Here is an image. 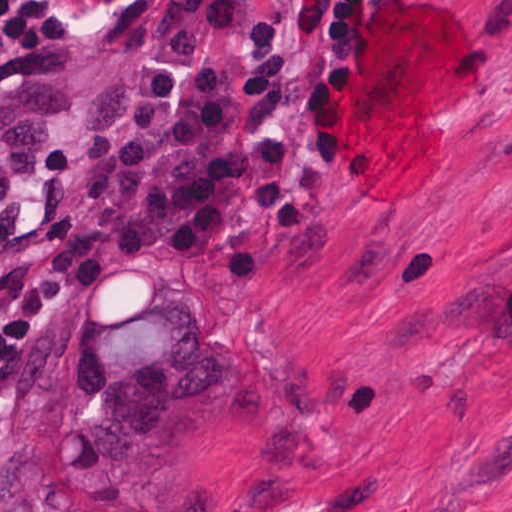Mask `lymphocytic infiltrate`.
<instances>
[{
  "label": "lymphocytic infiltrate",
  "mask_w": 512,
  "mask_h": 512,
  "mask_svg": "<svg viewBox=\"0 0 512 512\" xmlns=\"http://www.w3.org/2000/svg\"><path fill=\"white\" fill-rule=\"evenodd\" d=\"M395 0H174L37 129L39 170L78 229L0 272V385L56 307L139 255L222 261L254 297L270 241L311 224L358 144L361 88ZM59 39L0 0V63Z\"/></svg>",
  "instance_id": "obj_1"
}]
</instances>
